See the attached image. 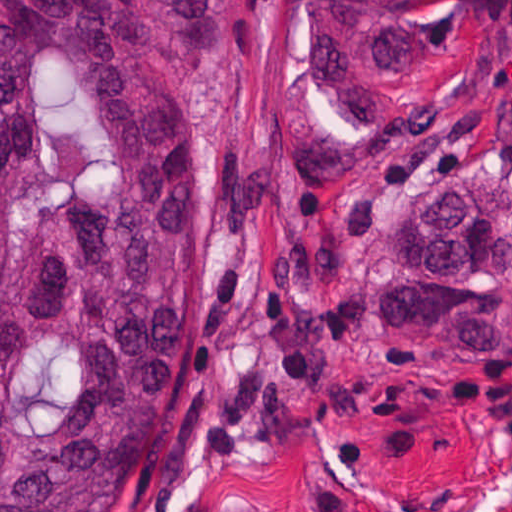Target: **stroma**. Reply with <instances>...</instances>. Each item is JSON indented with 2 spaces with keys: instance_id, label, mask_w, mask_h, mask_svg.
<instances>
[{
  "instance_id": "35a3bbf8",
  "label": "stroma",
  "mask_w": 512,
  "mask_h": 512,
  "mask_svg": "<svg viewBox=\"0 0 512 512\" xmlns=\"http://www.w3.org/2000/svg\"><path fill=\"white\" fill-rule=\"evenodd\" d=\"M292 18L209 0L185 67L203 293L165 380L180 437L118 512H512V346H428L364 297L437 170L502 177L512 230V0H435L392 127L324 107Z\"/></svg>"
}]
</instances>
